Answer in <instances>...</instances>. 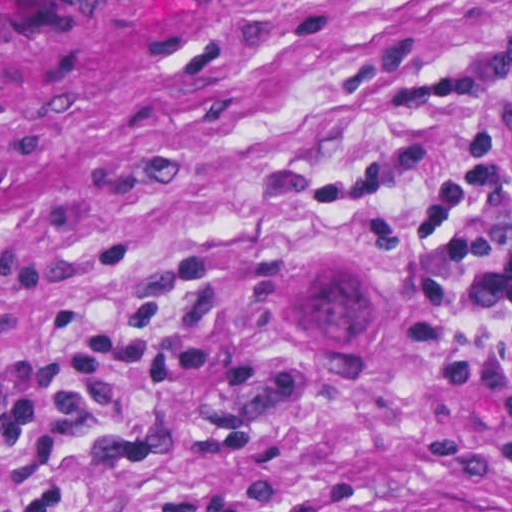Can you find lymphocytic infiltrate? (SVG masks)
Returning <instances> with one entry per match:
<instances>
[{"mask_svg":"<svg viewBox=\"0 0 512 512\" xmlns=\"http://www.w3.org/2000/svg\"><path fill=\"white\" fill-rule=\"evenodd\" d=\"M484 87L482 69L439 73L406 52L375 100L331 143L324 186L385 247L446 399L479 394L503 415V438L487 457L512 476V162L488 158L447 194L396 206L453 161L456 146L417 139L357 161L342 152L364 129L468 117Z\"/></svg>","mask_w":512,"mask_h":512,"instance_id":"lymphocytic-infiltrate-1","label":"lymphocytic infiltrate"}]
</instances>
